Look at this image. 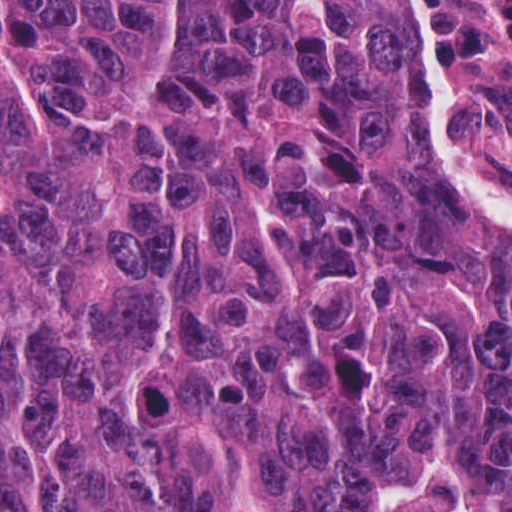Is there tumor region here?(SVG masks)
Listing matches in <instances>:
<instances>
[{"label":"tumor region","mask_w":512,"mask_h":512,"mask_svg":"<svg viewBox=\"0 0 512 512\" xmlns=\"http://www.w3.org/2000/svg\"><path fill=\"white\" fill-rule=\"evenodd\" d=\"M425 119L388 0H0V512H512Z\"/></svg>","instance_id":"obj_1"}]
</instances>
